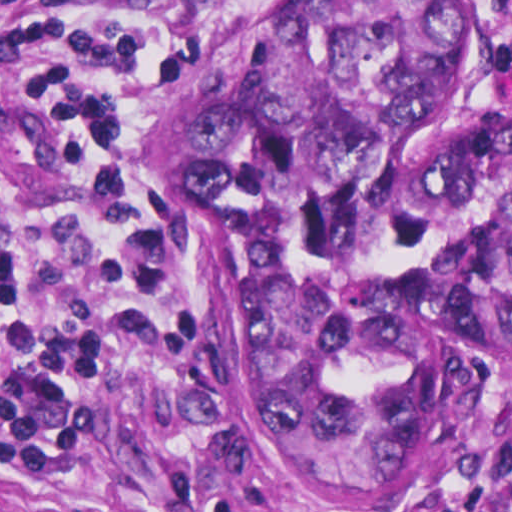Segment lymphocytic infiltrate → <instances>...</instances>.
Listing matches in <instances>:
<instances>
[{
	"instance_id": "f902f5d3",
	"label": "lymphocytic infiltrate",
	"mask_w": 512,
	"mask_h": 512,
	"mask_svg": "<svg viewBox=\"0 0 512 512\" xmlns=\"http://www.w3.org/2000/svg\"><path fill=\"white\" fill-rule=\"evenodd\" d=\"M241 0H86L14 31L2 63L42 85L60 118L71 194L60 222L26 223L0 163V477L54 488L99 432V372L150 365L179 404L209 400L210 338L186 274L147 243L106 175L102 116L136 60ZM512 32V0H496ZM504 76L512 80V52ZM198 468H174L170 512ZM212 512H229L226 507ZM463 512H512V477Z\"/></svg>"
}]
</instances>
